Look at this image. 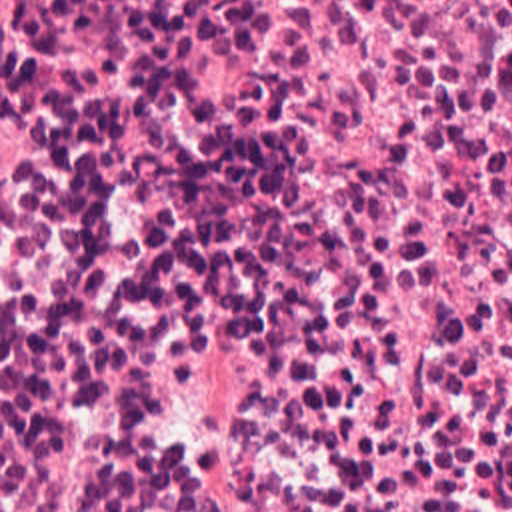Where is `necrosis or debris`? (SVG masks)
Returning <instances> with one entry per match:
<instances>
[{"label": "necrosis or debris", "instance_id": "4bbe7bcc", "mask_svg": "<svg viewBox=\"0 0 512 512\" xmlns=\"http://www.w3.org/2000/svg\"><path fill=\"white\" fill-rule=\"evenodd\" d=\"M0 428H512V0H0Z\"/></svg>", "mask_w": 512, "mask_h": 512}]
</instances>
